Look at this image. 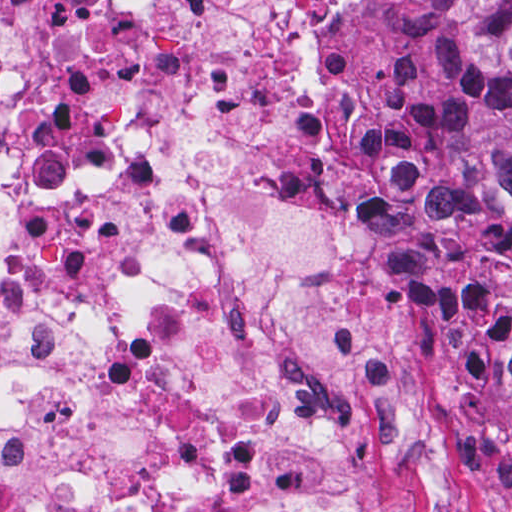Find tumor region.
Wrapping results in <instances>:
<instances>
[{"label":"tumor region","instance_id":"obj_1","mask_svg":"<svg viewBox=\"0 0 512 512\" xmlns=\"http://www.w3.org/2000/svg\"><path fill=\"white\" fill-rule=\"evenodd\" d=\"M446 2L458 69L449 175L490 268L493 350L512 411V0Z\"/></svg>","mask_w":512,"mask_h":512}]
</instances>
